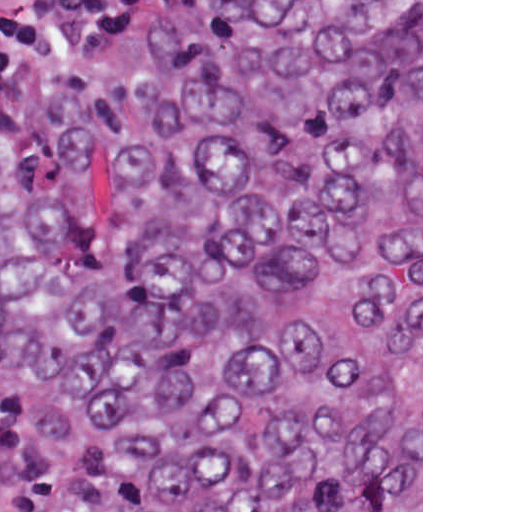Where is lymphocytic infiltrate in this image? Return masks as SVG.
<instances>
[{"mask_svg": "<svg viewBox=\"0 0 512 512\" xmlns=\"http://www.w3.org/2000/svg\"><path fill=\"white\" fill-rule=\"evenodd\" d=\"M165 0H0V126L35 103L134 90ZM0 512H51V490L0 402Z\"/></svg>", "mask_w": 512, "mask_h": 512, "instance_id": "1", "label": "lymphocytic infiltrate"}]
</instances>
